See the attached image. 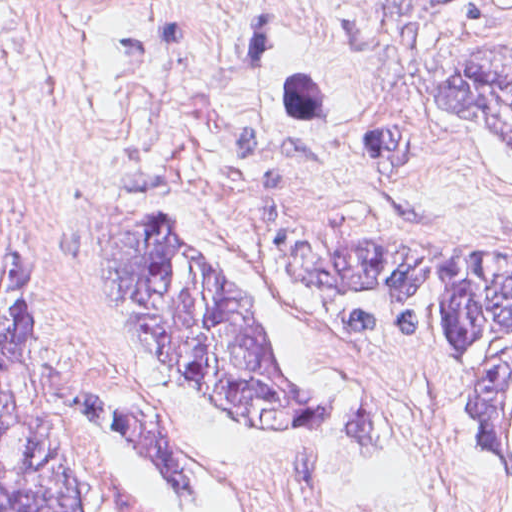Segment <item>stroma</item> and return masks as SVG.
I'll use <instances>...</instances> for the list:
<instances>
[{
	"label": "stroma",
	"instance_id": "1",
	"mask_svg": "<svg viewBox=\"0 0 512 512\" xmlns=\"http://www.w3.org/2000/svg\"><path fill=\"white\" fill-rule=\"evenodd\" d=\"M485 51H512V0H0V512L1 302L22 290L60 311L68 368L145 397L209 490L179 496L118 425L78 417L98 512H512L479 474L465 367L339 353L267 240L325 195L376 192L512 241V147L434 96ZM90 189L205 249L294 392L368 397L390 435L235 432L62 241Z\"/></svg>",
	"mask_w": 512,
	"mask_h": 512
}]
</instances>
